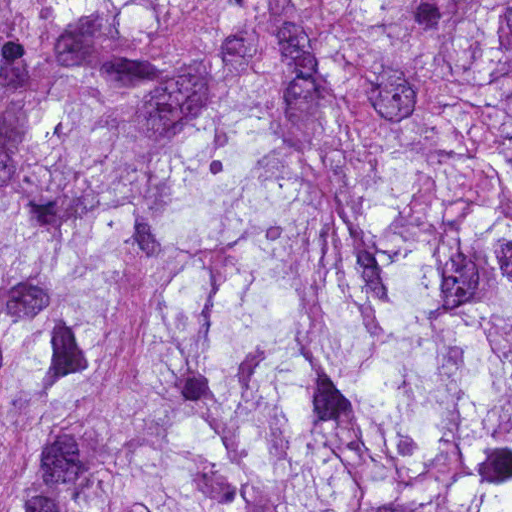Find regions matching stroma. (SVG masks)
Here are the masks:
<instances>
[{
	"instance_id": "obj_1",
	"label": "stroma",
	"mask_w": 512,
	"mask_h": 512,
	"mask_svg": "<svg viewBox=\"0 0 512 512\" xmlns=\"http://www.w3.org/2000/svg\"><path fill=\"white\" fill-rule=\"evenodd\" d=\"M1 1H512V0H0V512H1Z\"/></svg>"
}]
</instances>
